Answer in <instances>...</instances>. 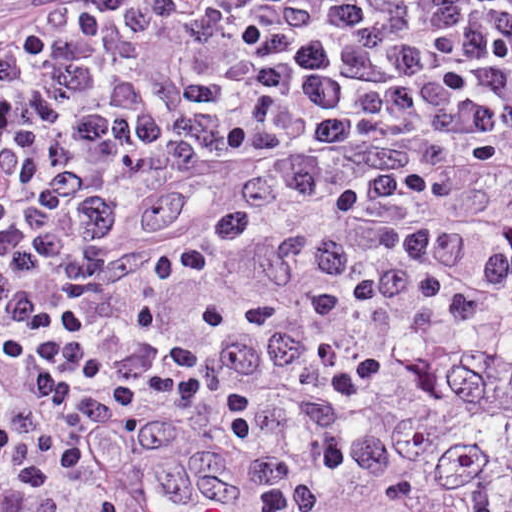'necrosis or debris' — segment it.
Here are the masks:
<instances>
[{
  "instance_id": "1",
  "label": "necrosis or debris",
  "mask_w": 512,
  "mask_h": 512,
  "mask_svg": "<svg viewBox=\"0 0 512 512\" xmlns=\"http://www.w3.org/2000/svg\"><path fill=\"white\" fill-rule=\"evenodd\" d=\"M508 319L512 322V314H509V315H508ZM460 345H462V344H459V345H448V346H447V347H445L444 349L440 350V351H439V352H437L436 354H434V355H432L431 357H429L428 359L424 360L423 362H421V364H420L418 367H416V368H415L411 373H409L405 378H403L400 382H398L397 384H395L394 386H392L390 389H388V390H387V391H386V392H385V393H384L380 398L384 397L388 392H390V391H392V390H394V389H396V388H398V387H400V386H402V385L406 384V383H407V381L410 379V377L413 375V373H414L416 370H418V369H419L423 364H425V363H426V362H428L430 359H432L434 356H436V355H438V354H440V353H443V352H445V351H448V350H450V349H453V348H455V347H458V346H460ZM380 398H379V399H380ZM379 399H378V400H379ZM378 400H377V401H378Z\"/></svg>"
}]
</instances>
